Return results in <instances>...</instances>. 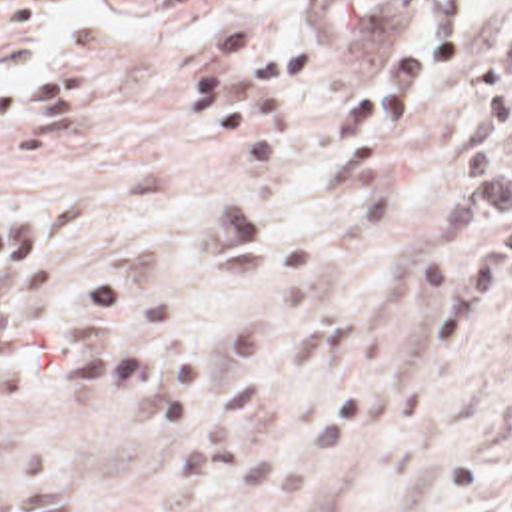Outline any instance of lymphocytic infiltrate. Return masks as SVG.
Here are the masks:
<instances>
[{
    "label": "lymphocytic infiltrate",
    "mask_w": 512,
    "mask_h": 512,
    "mask_svg": "<svg viewBox=\"0 0 512 512\" xmlns=\"http://www.w3.org/2000/svg\"><path fill=\"white\" fill-rule=\"evenodd\" d=\"M264 1L300 5L298 23L276 31L242 13L204 27L168 81L164 127L178 141H240L256 181L282 159L296 103L344 51H362L344 103L346 173L358 191H390L467 63L465 35L440 29L414 45L372 53L356 45L350 23L368 15L364 0Z\"/></svg>",
    "instance_id": "f902f5d3"
}]
</instances>
